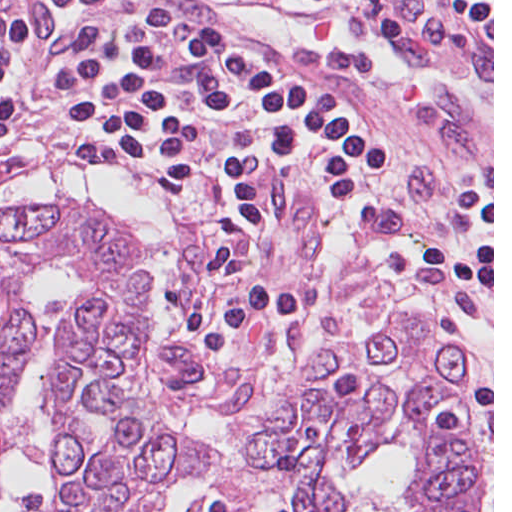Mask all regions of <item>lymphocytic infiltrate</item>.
Masks as SVG:
<instances>
[{"label": "lymphocytic infiltrate", "mask_w": 512, "mask_h": 512, "mask_svg": "<svg viewBox=\"0 0 512 512\" xmlns=\"http://www.w3.org/2000/svg\"><path fill=\"white\" fill-rule=\"evenodd\" d=\"M25 30L21 16L11 15L0 10V38Z\"/></svg>", "instance_id": "lymphocytic-infiltrate-1"}]
</instances>
